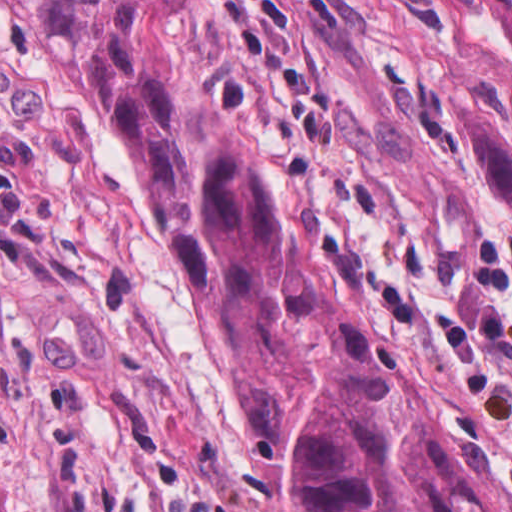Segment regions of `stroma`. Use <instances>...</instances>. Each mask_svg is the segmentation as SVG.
<instances>
[{
    "label": "stroma",
    "instance_id": "1",
    "mask_svg": "<svg viewBox=\"0 0 512 512\" xmlns=\"http://www.w3.org/2000/svg\"><path fill=\"white\" fill-rule=\"evenodd\" d=\"M175 43L257 146L303 265L424 362L512 479V204L452 148L463 75L512 124L484 0H184ZM7 512H295L204 325L188 250L0 0Z\"/></svg>",
    "mask_w": 512,
    "mask_h": 512
}]
</instances>
